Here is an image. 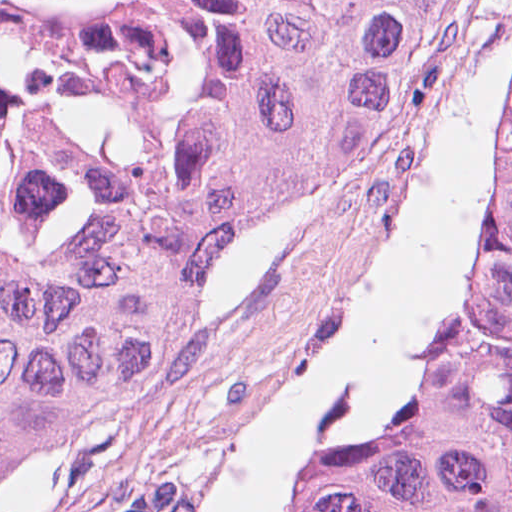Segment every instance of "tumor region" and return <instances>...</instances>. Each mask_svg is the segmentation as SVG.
Returning a JSON list of instances; mask_svg holds the SVG:
<instances>
[{"label": "tumor region", "instance_id": "e687c5a6", "mask_svg": "<svg viewBox=\"0 0 512 512\" xmlns=\"http://www.w3.org/2000/svg\"><path fill=\"white\" fill-rule=\"evenodd\" d=\"M449 2L187 0L184 126L138 218L0 282V498L140 389L205 286L302 220ZM298 512H512V75L503 196L401 442L331 464Z\"/></svg>", "mask_w": 512, "mask_h": 512}]
</instances>
